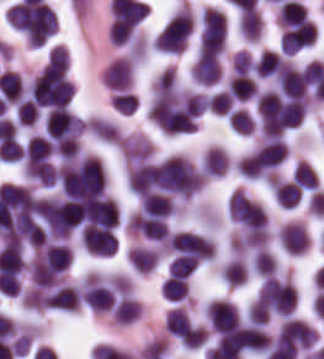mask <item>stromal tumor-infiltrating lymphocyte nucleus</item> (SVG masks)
<instances>
[{
    "mask_svg": "<svg viewBox=\"0 0 324 359\" xmlns=\"http://www.w3.org/2000/svg\"><path fill=\"white\" fill-rule=\"evenodd\" d=\"M225 42L226 19L221 11L207 6L201 16L199 53H219L225 49Z\"/></svg>",
    "mask_w": 324,
    "mask_h": 359,
    "instance_id": "obj_3",
    "label": "stromal tumor-infiltrating lymphocyte nucleus"
},
{
    "mask_svg": "<svg viewBox=\"0 0 324 359\" xmlns=\"http://www.w3.org/2000/svg\"><path fill=\"white\" fill-rule=\"evenodd\" d=\"M317 29L309 21L296 22L282 32L280 48L283 54H294L315 43Z\"/></svg>",
    "mask_w": 324,
    "mask_h": 359,
    "instance_id": "obj_8",
    "label": "stromal tumor-infiltrating lymphocyte nucleus"
},
{
    "mask_svg": "<svg viewBox=\"0 0 324 359\" xmlns=\"http://www.w3.org/2000/svg\"><path fill=\"white\" fill-rule=\"evenodd\" d=\"M165 298L180 300L188 294V285L182 276L169 275L161 284Z\"/></svg>",
    "mask_w": 324,
    "mask_h": 359,
    "instance_id": "obj_28",
    "label": "stromal tumor-infiltrating lymphocyte nucleus"
},
{
    "mask_svg": "<svg viewBox=\"0 0 324 359\" xmlns=\"http://www.w3.org/2000/svg\"><path fill=\"white\" fill-rule=\"evenodd\" d=\"M167 242L176 255L201 261L210 259L215 252L214 242L209 237L188 231L170 233Z\"/></svg>",
    "mask_w": 324,
    "mask_h": 359,
    "instance_id": "obj_4",
    "label": "stromal tumor-infiltrating lymphocyte nucleus"
},
{
    "mask_svg": "<svg viewBox=\"0 0 324 359\" xmlns=\"http://www.w3.org/2000/svg\"><path fill=\"white\" fill-rule=\"evenodd\" d=\"M248 268L242 258H234L222 267V275L227 284L238 285L246 280Z\"/></svg>",
    "mask_w": 324,
    "mask_h": 359,
    "instance_id": "obj_27",
    "label": "stromal tumor-infiltrating lymphocyte nucleus"
},
{
    "mask_svg": "<svg viewBox=\"0 0 324 359\" xmlns=\"http://www.w3.org/2000/svg\"><path fill=\"white\" fill-rule=\"evenodd\" d=\"M234 73L248 74L253 69V61L246 49H239L233 58Z\"/></svg>",
    "mask_w": 324,
    "mask_h": 359,
    "instance_id": "obj_33",
    "label": "stromal tumor-infiltrating lymphocyte nucleus"
},
{
    "mask_svg": "<svg viewBox=\"0 0 324 359\" xmlns=\"http://www.w3.org/2000/svg\"><path fill=\"white\" fill-rule=\"evenodd\" d=\"M82 297L95 312L110 310L115 301L113 280L85 278L82 280Z\"/></svg>",
    "mask_w": 324,
    "mask_h": 359,
    "instance_id": "obj_5",
    "label": "stromal tumor-infiltrating lymphocyte nucleus"
},
{
    "mask_svg": "<svg viewBox=\"0 0 324 359\" xmlns=\"http://www.w3.org/2000/svg\"><path fill=\"white\" fill-rule=\"evenodd\" d=\"M7 19L32 45H41L55 32L57 16L45 1L23 0L7 10Z\"/></svg>",
    "mask_w": 324,
    "mask_h": 359,
    "instance_id": "obj_1",
    "label": "stromal tumor-infiltrating lymphocyte nucleus"
},
{
    "mask_svg": "<svg viewBox=\"0 0 324 359\" xmlns=\"http://www.w3.org/2000/svg\"><path fill=\"white\" fill-rule=\"evenodd\" d=\"M272 188L281 206L290 208L302 197V191L294 181L273 178Z\"/></svg>",
    "mask_w": 324,
    "mask_h": 359,
    "instance_id": "obj_22",
    "label": "stromal tumor-infiltrating lymphocyte nucleus"
},
{
    "mask_svg": "<svg viewBox=\"0 0 324 359\" xmlns=\"http://www.w3.org/2000/svg\"><path fill=\"white\" fill-rule=\"evenodd\" d=\"M168 341L162 336H155L143 344L139 355L141 359H153L163 355L167 349Z\"/></svg>",
    "mask_w": 324,
    "mask_h": 359,
    "instance_id": "obj_32",
    "label": "stromal tumor-infiltrating lymphocyte nucleus"
},
{
    "mask_svg": "<svg viewBox=\"0 0 324 359\" xmlns=\"http://www.w3.org/2000/svg\"><path fill=\"white\" fill-rule=\"evenodd\" d=\"M288 146L279 138H266L257 150L262 176L274 169L287 156Z\"/></svg>",
    "mask_w": 324,
    "mask_h": 359,
    "instance_id": "obj_15",
    "label": "stromal tumor-infiltrating lymphocyte nucleus"
},
{
    "mask_svg": "<svg viewBox=\"0 0 324 359\" xmlns=\"http://www.w3.org/2000/svg\"><path fill=\"white\" fill-rule=\"evenodd\" d=\"M130 229L144 238L162 240L168 227L162 218L138 211L130 218Z\"/></svg>",
    "mask_w": 324,
    "mask_h": 359,
    "instance_id": "obj_16",
    "label": "stromal tumor-infiltrating lymphocyte nucleus"
},
{
    "mask_svg": "<svg viewBox=\"0 0 324 359\" xmlns=\"http://www.w3.org/2000/svg\"><path fill=\"white\" fill-rule=\"evenodd\" d=\"M282 248L288 254H303L309 245V234L303 224L288 221L278 232Z\"/></svg>",
    "mask_w": 324,
    "mask_h": 359,
    "instance_id": "obj_13",
    "label": "stromal tumor-infiltrating lymphocyte nucleus"
},
{
    "mask_svg": "<svg viewBox=\"0 0 324 359\" xmlns=\"http://www.w3.org/2000/svg\"><path fill=\"white\" fill-rule=\"evenodd\" d=\"M294 181L303 190H315L317 177L312 166L305 160H298L294 167Z\"/></svg>",
    "mask_w": 324,
    "mask_h": 359,
    "instance_id": "obj_25",
    "label": "stromal tumor-infiltrating lymphocyte nucleus"
},
{
    "mask_svg": "<svg viewBox=\"0 0 324 359\" xmlns=\"http://www.w3.org/2000/svg\"><path fill=\"white\" fill-rule=\"evenodd\" d=\"M292 65L282 56L269 49H262L254 73L259 78L280 79Z\"/></svg>",
    "mask_w": 324,
    "mask_h": 359,
    "instance_id": "obj_14",
    "label": "stromal tumor-infiltrating lymphocyte nucleus"
},
{
    "mask_svg": "<svg viewBox=\"0 0 324 359\" xmlns=\"http://www.w3.org/2000/svg\"><path fill=\"white\" fill-rule=\"evenodd\" d=\"M192 75L198 84L211 85L220 78V63L216 54H198Z\"/></svg>",
    "mask_w": 324,
    "mask_h": 359,
    "instance_id": "obj_17",
    "label": "stromal tumor-infiltrating lymphocyte nucleus"
},
{
    "mask_svg": "<svg viewBox=\"0 0 324 359\" xmlns=\"http://www.w3.org/2000/svg\"><path fill=\"white\" fill-rule=\"evenodd\" d=\"M71 264V251L62 243H49L38 249L35 265L63 272Z\"/></svg>",
    "mask_w": 324,
    "mask_h": 359,
    "instance_id": "obj_12",
    "label": "stromal tumor-infiltrating lymphocyte nucleus"
},
{
    "mask_svg": "<svg viewBox=\"0 0 324 359\" xmlns=\"http://www.w3.org/2000/svg\"><path fill=\"white\" fill-rule=\"evenodd\" d=\"M229 165V156L223 147L209 146L201 161V169L208 175H221Z\"/></svg>",
    "mask_w": 324,
    "mask_h": 359,
    "instance_id": "obj_19",
    "label": "stromal tumor-infiltrating lymphocyte nucleus"
},
{
    "mask_svg": "<svg viewBox=\"0 0 324 359\" xmlns=\"http://www.w3.org/2000/svg\"><path fill=\"white\" fill-rule=\"evenodd\" d=\"M235 169L245 178H255L262 174V167L256 150H252L235 162Z\"/></svg>",
    "mask_w": 324,
    "mask_h": 359,
    "instance_id": "obj_26",
    "label": "stromal tumor-infiltrating lymphocyte nucleus"
},
{
    "mask_svg": "<svg viewBox=\"0 0 324 359\" xmlns=\"http://www.w3.org/2000/svg\"><path fill=\"white\" fill-rule=\"evenodd\" d=\"M241 33L249 41H258L262 32V21L256 11H242L239 18Z\"/></svg>",
    "mask_w": 324,
    "mask_h": 359,
    "instance_id": "obj_24",
    "label": "stromal tumor-infiltrating lymphocyte nucleus"
},
{
    "mask_svg": "<svg viewBox=\"0 0 324 359\" xmlns=\"http://www.w3.org/2000/svg\"><path fill=\"white\" fill-rule=\"evenodd\" d=\"M81 292L75 284H61L45 290L41 305L61 311H77Z\"/></svg>",
    "mask_w": 324,
    "mask_h": 359,
    "instance_id": "obj_10",
    "label": "stromal tumor-infiltrating lymphocyte nucleus"
},
{
    "mask_svg": "<svg viewBox=\"0 0 324 359\" xmlns=\"http://www.w3.org/2000/svg\"><path fill=\"white\" fill-rule=\"evenodd\" d=\"M141 211L155 215L168 216L174 209V201L166 194L149 193L143 195L140 203Z\"/></svg>",
    "mask_w": 324,
    "mask_h": 359,
    "instance_id": "obj_21",
    "label": "stromal tumor-infiltrating lymphocyte nucleus"
},
{
    "mask_svg": "<svg viewBox=\"0 0 324 359\" xmlns=\"http://www.w3.org/2000/svg\"><path fill=\"white\" fill-rule=\"evenodd\" d=\"M83 127V120L66 106L49 110L45 119L46 133L51 138H74Z\"/></svg>",
    "mask_w": 324,
    "mask_h": 359,
    "instance_id": "obj_6",
    "label": "stromal tumor-infiltrating lymphocyte nucleus"
},
{
    "mask_svg": "<svg viewBox=\"0 0 324 359\" xmlns=\"http://www.w3.org/2000/svg\"><path fill=\"white\" fill-rule=\"evenodd\" d=\"M193 30L188 7H181L155 37V48L164 52H183Z\"/></svg>",
    "mask_w": 324,
    "mask_h": 359,
    "instance_id": "obj_2",
    "label": "stromal tumor-infiltrating lymphocyte nucleus"
},
{
    "mask_svg": "<svg viewBox=\"0 0 324 359\" xmlns=\"http://www.w3.org/2000/svg\"><path fill=\"white\" fill-rule=\"evenodd\" d=\"M108 89L129 90L133 84L134 62L131 56L115 58L104 69Z\"/></svg>",
    "mask_w": 324,
    "mask_h": 359,
    "instance_id": "obj_11",
    "label": "stromal tumor-infiltrating lymphocyte nucleus"
},
{
    "mask_svg": "<svg viewBox=\"0 0 324 359\" xmlns=\"http://www.w3.org/2000/svg\"><path fill=\"white\" fill-rule=\"evenodd\" d=\"M206 317L212 330L217 333L240 324L239 309L226 299H213L207 308Z\"/></svg>",
    "mask_w": 324,
    "mask_h": 359,
    "instance_id": "obj_9",
    "label": "stromal tumor-infiltrating lymphocyte nucleus"
},
{
    "mask_svg": "<svg viewBox=\"0 0 324 359\" xmlns=\"http://www.w3.org/2000/svg\"><path fill=\"white\" fill-rule=\"evenodd\" d=\"M52 153V142L49 137L40 133L30 135L23 151L28 164H36L45 160Z\"/></svg>",
    "mask_w": 324,
    "mask_h": 359,
    "instance_id": "obj_18",
    "label": "stromal tumor-infiltrating lymphocyte nucleus"
},
{
    "mask_svg": "<svg viewBox=\"0 0 324 359\" xmlns=\"http://www.w3.org/2000/svg\"><path fill=\"white\" fill-rule=\"evenodd\" d=\"M229 92L236 101H247L257 93L256 85L251 77L234 74L228 79Z\"/></svg>",
    "mask_w": 324,
    "mask_h": 359,
    "instance_id": "obj_23",
    "label": "stromal tumor-infiltrating lymphocyte nucleus"
},
{
    "mask_svg": "<svg viewBox=\"0 0 324 359\" xmlns=\"http://www.w3.org/2000/svg\"><path fill=\"white\" fill-rule=\"evenodd\" d=\"M251 266L263 277L276 273L277 262L267 249L261 248L252 256Z\"/></svg>",
    "mask_w": 324,
    "mask_h": 359,
    "instance_id": "obj_29",
    "label": "stromal tumor-infiltrating lymphocyte nucleus"
},
{
    "mask_svg": "<svg viewBox=\"0 0 324 359\" xmlns=\"http://www.w3.org/2000/svg\"><path fill=\"white\" fill-rule=\"evenodd\" d=\"M230 127L239 132H252L255 120L249 110L237 107L229 115Z\"/></svg>",
    "mask_w": 324,
    "mask_h": 359,
    "instance_id": "obj_30",
    "label": "stromal tumor-infiltrating lymphocyte nucleus"
},
{
    "mask_svg": "<svg viewBox=\"0 0 324 359\" xmlns=\"http://www.w3.org/2000/svg\"><path fill=\"white\" fill-rule=\"evenodd\" d=\"M128 259L139 273H147L160 259L157 248L134 246L128 252Z\"/></svg>",
    "mask_w": 324,
    "mask_h": 359,
    "instance_id": "obj_20",
    "label": "stromal tumor-infiltrating lymphocyte nucleus"
},
{
    "mask_svg": "<svg viewBox=\"0 0 324 359\" xmlns=\"http://www.w3.org/2000/svg\"><path fill=\"white\" fill-rule=\"evenodd\" d=\"M197 266V260L186 254H178L171 260L169 274L187 277Z\"/></svg>",
    "mask_w": 324,
    "mask_h": 359,
    "instance_id": "obj_31",
    "label": "stromal tumor-infiltrating lymphocyte nucleus"
},
{
    "mask_svg": "<svg viewBox=\"0 0 324 359\" xmlns=\"http://www.w3.org/2000/svg\"><path fill=\"white\" fill-rule=\"evenodd\" d=\"M316 333L308 323L299 318H286L276 338V343L293 348H310Z\"/></svg>",
    "mask_w": 324,
    "mask_h": 359,
    "instance_id": "obj_7",
    "label": "stromal tumor-infiltrating lymphocyte nucleus"
}]
</instances>
